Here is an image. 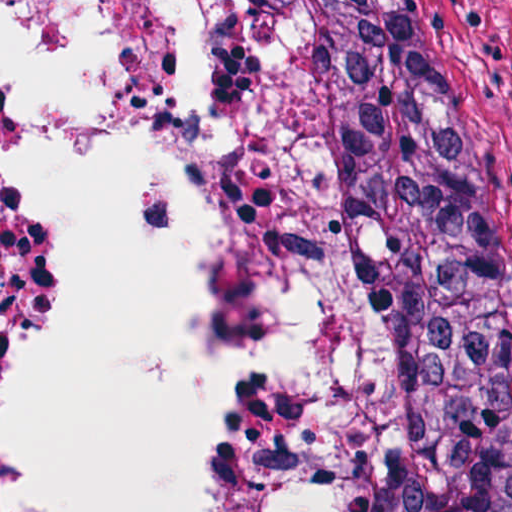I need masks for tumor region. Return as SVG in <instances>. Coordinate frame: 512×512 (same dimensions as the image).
Returning a JSON list of instances; mask_svg holds the SVG:
<instances>
[{"label": "tumor region", "mask_w": 512, "mask_h": 512, "mask_svg": "<svg viewBox=\"0 0 512 512\" xmlns=\"http://www.w3.org/2000/svg\"><path fill=\"white\" fill-rule=\"evenodd\" d=\"M352 309L378 512H505L441 0H227Z\"/></svg>", "instance_id": "1"}]
</instances>
